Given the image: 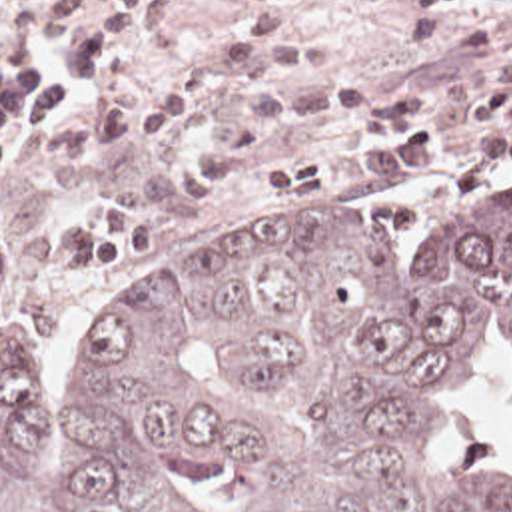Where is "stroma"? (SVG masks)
I'll return each mask as SVG.
<instances>
[{
	"mask_svg": "<svg viewBox=\"0 0 512 512\" xmlns=\"http://www.w3.org/2000/svg\"><path fill=\"white\" fill-rule=\"evenodd\" d=\"M16 0H0V25ZM248 0H176L170 33L150 49L118 95L138 97L170 75L234 41L254 15ZM285 27L299 41L329 49V73L279 93L285 99L321 83H367L381 95L421 79L445 77L463 63L512 47V0H463L433 17H411L401 0H299ZM512 89L497 83L443 103L427 117L437 139L433 160L339 180L289 200L265 198L275 162L301 150L351 141L349 123L299 129L252 156L222 192L188 214L138 262L88 276H26L10 260V244L28 226L96 206L118 192L190 162L218 141L234 91H220L184 115L170 139L70 164H36L28 146L0 170V284L14 286L42 348V404L72 400V348L156 260L186 254L252 228L311 226L335 218L377 230L403 272L449 240L465 238L512 206V160H479L473 141L503 129L471 109L473 95Z\"/></svg>",
	"mask_w": 512,
	"mask_h": 512,
	"instance_id": "1",
	"label": "stroma"
}]
</instances>
